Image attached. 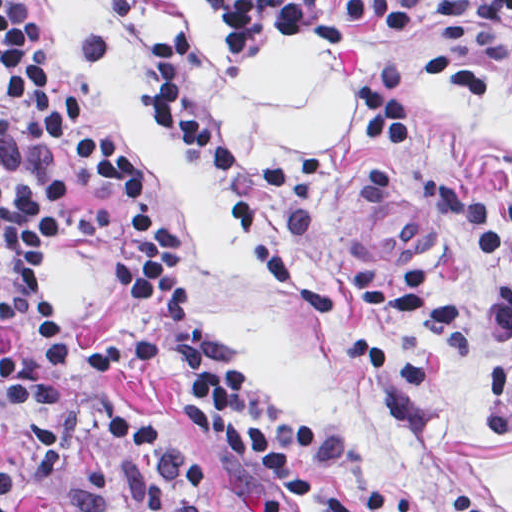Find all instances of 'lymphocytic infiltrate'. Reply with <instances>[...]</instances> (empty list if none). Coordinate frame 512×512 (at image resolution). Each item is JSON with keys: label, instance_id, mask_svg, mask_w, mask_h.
I'll list each match as a JSON object with an SVG mask.
<instances>
[{"label": "lymphocytic infiltrate", "instance_id": "obj_1", "mask_svg": "<svg viewBox=\"0 0 512 512\" xmlns=\"http://www.w3.org/2000/svg\"><path fill=\"white\" fill-rule=\"evenodd\" d=\"M36 0H0V43ZM307 23L326 41L388 58L355 87L350 128L296 162L228 148L204 115L183 101L203 27L183 19L156 30L146 80L176 144L211 165L220 196L288 301L341 330L371 366L392 424L413 419L433 377L431 362L364 331L368 311H391L446 348L473 359L505 346L495 375V431L512 437V286L490 291L472 314L420 265L404 273L345 268L330 280L270 239L268 202L321 195L331 169L377 148L413 145V64H490L512 70L509 0H303ZM79 177L99 190H130L136 157L81 118L62 81L40 13L0 67V512L31 489L78 512H219L193 459L104 392L77 388L65 367V322L52 257L70 248L108 264L121 299L89 371L106 382L173 377L180 417L214 450L231 512H358L343 487L308 475L313 436L284 416L176 275L150 201L107 212L68 191ZM421 203L479 258L512 264V208L474 206L436 182L414 185ZM460 512H500L453 489Z\"/></svg>", "mask_w": 512, "mask_h": 512}]
</instances>
